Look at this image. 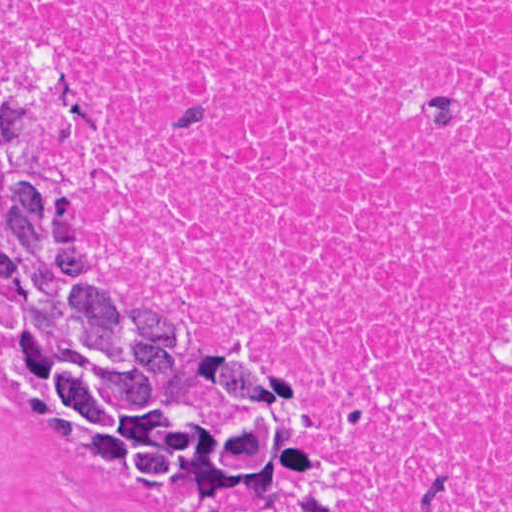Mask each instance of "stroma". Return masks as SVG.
<instances>
[{"label":"stroma","instance_id":"obj_1","mask_svg":"<svg viewBox=\"0 0 512 512\" xmlns=\"http://www.w3.org/2000/svg\"><path fill=\"white\" fill-rule=\"evenodd\" d=\"M0 1H512V0H0ZM36 18H51L62 28L72 78L86 99V117L67 141L40 151V167L67 187L86 214V257L101 282L142 288L166 298L179 315L188 342L266 350L290 357L307 384V422L332 460L334 492L341 512H365L358 493L357 463L335 429L331 406L337 375L319 361L281 342L235 323H209L193 313L169 285L117 268L109 260V207L89 178L90 155L105 134V105L87 68L91 33L99 27L89 13L33 17L22 22L6 42L0 61L16 54L23 29ZM0 512H177L154 497L145 485L104 469L69 459L51 439L36 407L0 381Z\"/></svg>","mask_w":512,"mask_h":512}]
</instances>
